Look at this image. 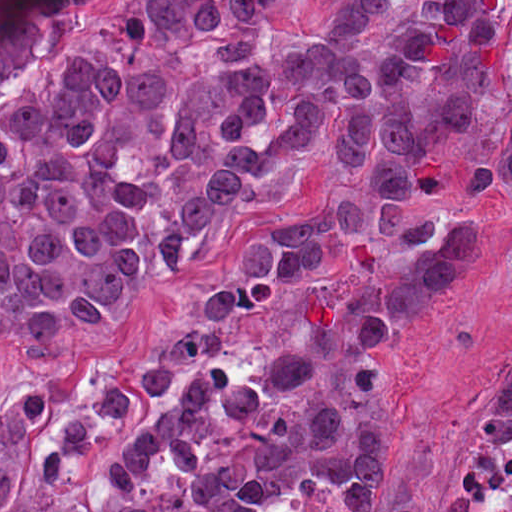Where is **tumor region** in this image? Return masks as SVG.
<instances>
[{
  "mask_svg": "<svg viewBox=\"0 0 512 512\" xmlns=\"http://www.w3.org/2000/svg\"><path fill=\"white\" fill-rule=\"evenodd\" d=\"M481 412L512 418V372L479 386ZM398 422L198 512H416L384 499V467Z\"/></svg>",
  "mask_w": 512,
  "mask_h": 512,
  "instance_id": "tumor-region-1",
  "label": "tumor region"
}]
</instances>
